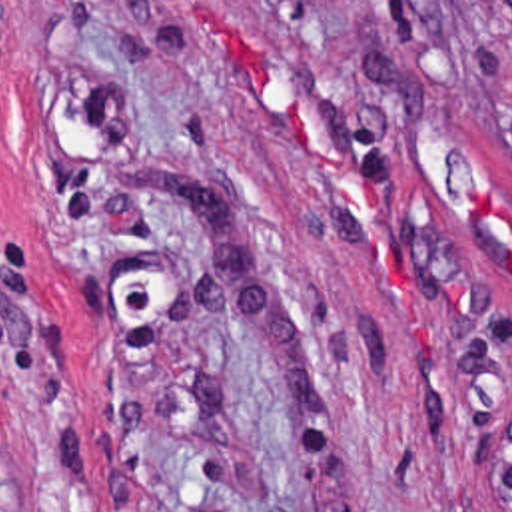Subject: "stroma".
<instances>
[{
  "instance_id": "obj_1",
  "label": "stroma",
  "mask_w": 512,
  "mask_h": 512,
  "mask_svg": "<svg viewBox=\"0 0 512 512\" xmlns=\"http://www.w3.org/2000/svg\"><path fill=\"white\" fill-rule=\"evenodd\" d=\"M502 2L0 0V512H486Z\"/></svg>"
}]
</instances>
